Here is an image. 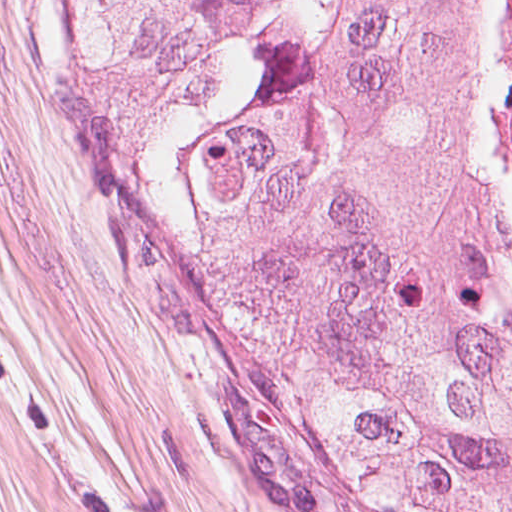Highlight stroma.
Here are the masks:
<instances>
[{"mask_svg": "<svg viewBox=\"0 0 512 512\" xmlns=\"http://www.w3.org/2000/svg\"><path fill=\"white\" fill-rule=\"evenodd\" d=\"M501 2H470L462 115L512 232L487 115ZM0 512H327L208 351L77 0H0Z\"/></svg>", "mask_w": 512, "mask_h": 512, "instance_id": "35a3bbf8", "label": "stroma"}]
</instances>
